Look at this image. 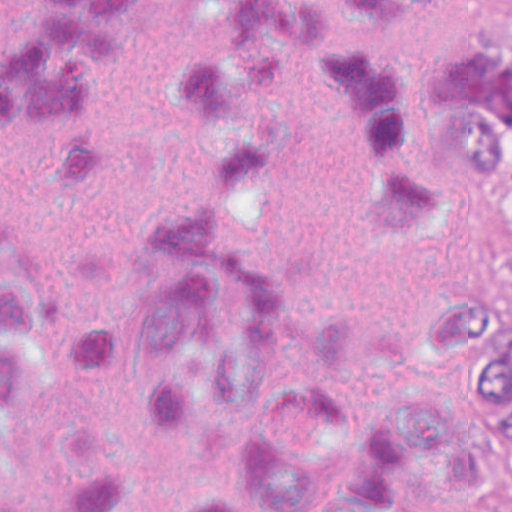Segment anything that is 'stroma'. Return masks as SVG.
I'll return each mask as SVG.
<instances>
[{
	"label": "stroma",
	"mask_w": 512,
	"mask_h": 512,
	"mask_svg": "<svg viewBox=\"0 0 512 512\" xmlns=\"http://www.w3.org/2000/svg\"><path fill=\"white\" fill-rule=\"evenodd\" d=\"M500 49L512 39V0H499ZM471 295L512 301V180L484 183L471 269Z\"/></svg>",
	"instance_id": "stroma-1"
}]
</instances>
